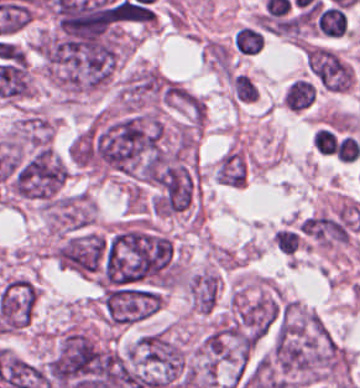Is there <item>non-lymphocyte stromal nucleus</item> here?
Masks as SVG:
<instances>
[{"label":"non-lymphocyte stromal nucleus","instance_id":"dd21d789","mask_svg":"<svg viewBox=\"0 0 360 388\" xmlns=\"http://www.w3.org/2000/svg\"><path fill=\"white\" fill-rule=\"evenodd\" d=\"M306 59L311 70L329 89L344 92L353 80V70L348 62L331 49L308 46Z\"/></svg>","mask_w":360,"mask_h":388}]
</instances>
